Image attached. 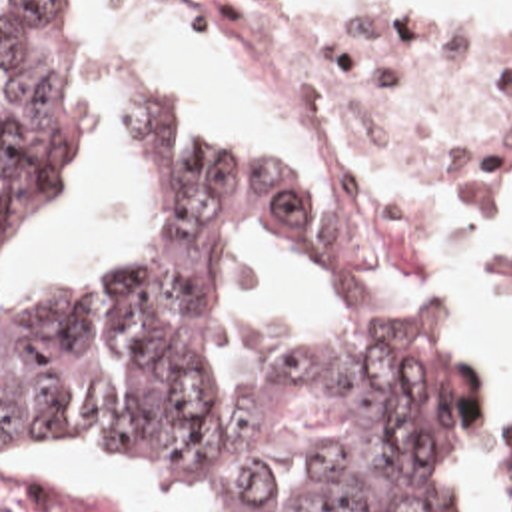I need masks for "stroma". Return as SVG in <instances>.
<instances>
[{
	"instance_id": "stroma-1",
	"label": "stroma",
	"mask_w": 512,
	"mask_h": 512,
	"mask_svg": "<svg viewBox=\"0 0 512 512\" xmlns=\"http://www.w3.org/2000/svg\"><path fill=\"white\" fill-rule=\"evenodd\" d=\"M70 25L82 33L98 53L124 73L152 75L116 47L90 19L80 0H56ZM170 11L190 33L208 41V21L220 0H154ZM282 21L304 37L333 49H512V29H445L381 5H319L310 0H262ZM156 77V75H154ZM250 77V75H248ZM288 121L306 137L304 119L268 85ZM306 193L325 227V255L311 261L315 273L343 297L347 307H391L409 315L431 317L461 332L455 317L439 307L429 285V259L439 245L451 239L473 217L489 211L503 195L493 197H419L407 225V261L379 277H369L345 259L329 225V183L315 159L304 171H294L274 149ZM512 195V193H511ZM0 241H2V0H0ZM497 297L512 305V253L499 265ZM485 376V406L489 430L465 468L453 498V512H512V502L501 496L489 472L493 438V408L497 400V358L479 342L463 336ZM2 474H56L78 478L120 494L134 512H196L192 506L134 470L120 450L92 444H36L22 440L2 408V309H0V512Z\"/></svg>"
}]
</instances>
